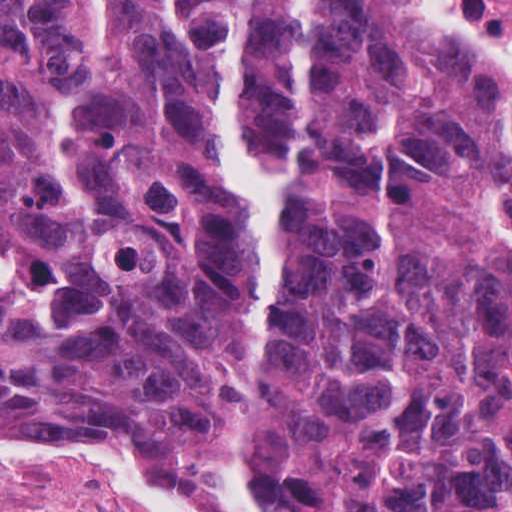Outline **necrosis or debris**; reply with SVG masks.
<instances>
[{
	"label": "necrosis or debris",
	"mask_w": 512,
	"mask_h": 512,
	"mask_svg": "<svg viewBox=\"0 0 512 512\" xmlns=\"http://www.w3.org/2000/svg\"><path fill=\"white\" fill-rule=\"evenodd\" d=\"M491 20L512 32V0H484Z\"/></svg>",
	"instance_id": "obj_1"
}]
</instances>
